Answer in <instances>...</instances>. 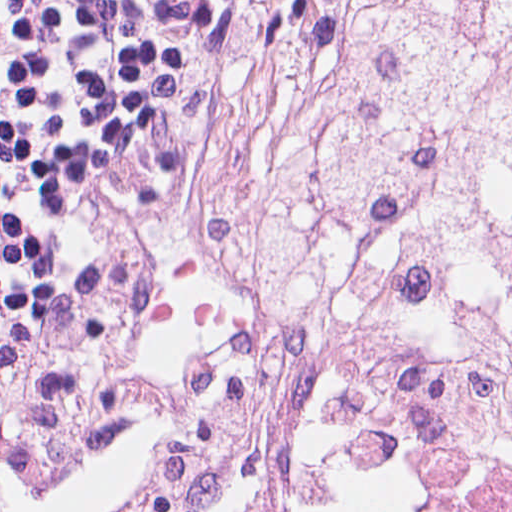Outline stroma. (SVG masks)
<instances>
[{
  "instance_id": "1",
  "label": "stroma",
  "mask_w": 512,
  "mask_h": 512,
  "mask_svg": "<svg viewBox=\"0 0 512 512\" xmlns=\"http://www.w3.org/2000/svg\"><path fill=\"white\" fill-rule=\"evenodd\" d=\"M220 42L86 259L0 352V512L65 459L140 426L115 512H172L209 382L284 252L277 0H220ZM400 457L444 512H512V452L396 373L350 389L315 463ZM304 512H310V484Z\"/></svg>"
}]
</instances>
